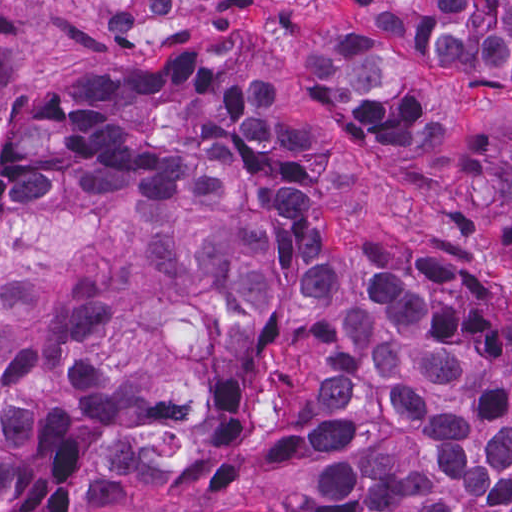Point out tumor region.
<instances>
[{
    "label": "tumor region",
    "mask_w": 512,
    "mask_h": 512,
    "mask_svg": "<svg viewBox=\"0 0 512 512\" xmlns=\"http://www.w3.org/2000/svg\"><path fill=\"white\" fill-rule=\"evenodd\" d=\"M388 171L512 261V1H0V512H512V305L329 250Z\"/></svg>",
    "instance_id": "e687c5a6"
}]
</instances>
